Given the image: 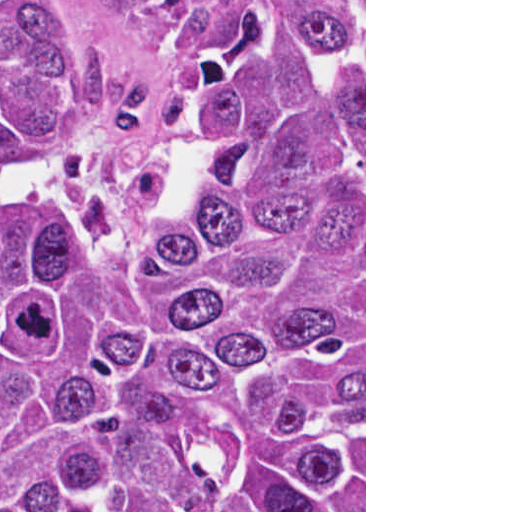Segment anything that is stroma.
I'll use <instances>...</instances> for the list:
<instances>
[{"label":"stroma","instance_id":"obj_1","mask_svg":"<svg viewBox=\"0 0 512 512\" xmlns=\"http://www.w3.org/2000/svg\"><path fill=\"white\" fill-rule=\"evenodd\" d=\"M364 5V512H366V0ZM241 0L159 11L147 0H87L91 60L104 125L98 138L45 167L85 181L122 220L141 218L196 173L200 55Z\"/></svg>","mask_w":512,"mask_h":512}]
</instances>
